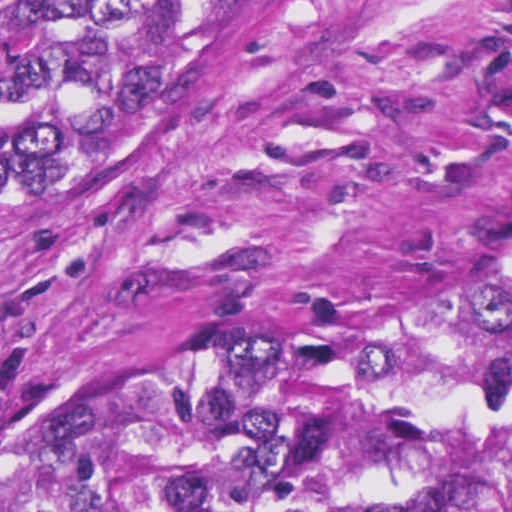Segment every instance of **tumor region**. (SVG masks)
<instances>
[{
  "label": "tumor region",
  "instance_id": "1",
  "mask_svg": "<svg viewBox=\"0 0 512 512\" xmlns=\"http://www.w3.org/2000/svg\"><path fill=\"white\" fill-rule=\"evenodd\" d=\"M294 0H0V127L220 87ZM0 512H512V222L169 359L0 465Z\"/></svg>",
  "mask_w": 512,
  "mask_h": 512
}]
</instances>
